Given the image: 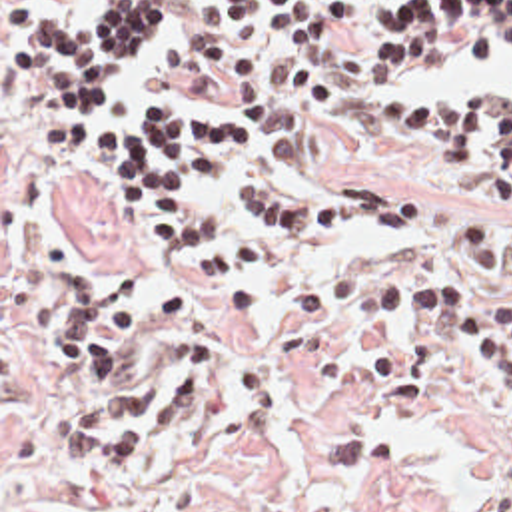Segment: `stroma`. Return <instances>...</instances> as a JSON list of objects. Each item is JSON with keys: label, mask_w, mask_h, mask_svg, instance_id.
I'll return each instance as SVG.
<instances>
[{"label": "stroma", "mask_w": 512, "mask_h": 512, "mask_svg": "<svg viewBox=\"0 0 512 512\" xmlns=\"http://www.w3.org/2000/svg\"><path fill=\"white\" fill-rule=\"evenodd\" d=\"M96 2L0 0V512H485L512 431L511 391L493 367L421 323L313 329L294 307L297 277L327 265L371 279L459 273L465 261L447 232L473 210L512 236V208L453 184L391 124L397 98L417 84L367 78L381 48L377 12L391 2L347 0L363 16L341 28L335 50H294L256 12L238 24L214 0H176V20L112 108L178 102L244 118L270 142V178L413 204V222L395 232L339 240L198 192L204 210L262 250L258 297L240 313L192 297L178 273L184 240L150 232L98 186L78 148L46 136L50 102L12 80L22 18L78 26ZM375 70L391 76L399 66ZM511 90L512 78L455 94ZM40 244L74 257L82 283L136 265L122 307L166 283L186 289L172 323L134 333V365L186 339L220 341L202 409L164 423V445L134 469L70 473L64 463L66 425L96 389L48 353V301L26 271ZM503 293L512 297V285Z\"/></svg>", "instance_id": "1"}]
</instances>
